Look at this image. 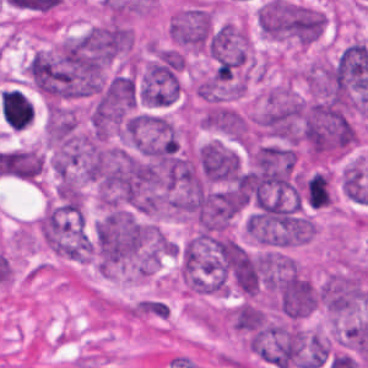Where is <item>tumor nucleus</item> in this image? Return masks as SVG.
I'll return each mask as SVG.
<instances>
[{"label": "tumor nucleus", "instance_id": "1", "mask_svg": "<svg viewBox=\"0 0 368 368\" xmlns=\"http://www.w3.org/2000/svg\"><path fill=\"white\" fill-rule=\"evenodd\" d=\"M292 117L300 148L311 160H327L348 152L357 141L350 107L315 94L300 96Z\"/></svg>", "mask_w": 368, "mask_h": 368}, {"label": "tumor nucleus", "instance_id": "2", "mask_svg": "<svg viewBox=\"0 0 368 368\" xmlns=\"http://www.w3.org/2000/svg\"><path fill=\"white\" fill-rule=\"evenodd\" d=\"M26 73L47 102L59 103L83 94L82 57L64 43L35 51L26 64Z\"/></svg>", "mask_w": 368, "mask_h": 368}, {"label": "tumor nucleus", "instance_id": "3", "mask_svg": "<svg viewBox=\"0 0 368 368\" xmlns=\"http://www.w3.org/2000/svg\"><path fill=\"white\" fill-rule=\"evenodd\" d=\"M185 56L175 48L151 46L136 77L135 98L145 106L171 107L182 92Z\"/></svg>", "mask_w": 368, "mask_h": 368}, {"label": "tumor nucleus", "instance_id": "4", "mask_svg": "<svg viewBox=\"0 0 368 368\" xmlns=\"http://www.w3.org/2000/svg\"><path fill=\"white\" fill-rule=\"evenodd\" d=\"M38 229L45 245L57 255L81 260L91 256V238L83 213L50 201Z\"/></svg>", "mask_w": 368, "mask_h": 368}, {"label": "tumor nucleus", "instance_id": "5", "mask_svg": "<svg viewBox=\"0 0 368 368\" xmlns=\"http://www.w3.org/2000/svg\"><path fill=\"white\" fill-rule=\"evenodd\" d=\"M300 95L284 85L268 86L256 111L258 133L296 146Z\"/></svg>", "mask_w": 368, "mask_h": 368}, {"label": "tumor nucleus", "instance_id": "6", "mask_svg": "<svg viewBox=\"0 0 368 368\" xmlns=\"http://www.w3.org/2000/svg\"><path fill=\"white\" fill-rule=\"evenodd\" d=\"M368 300V269L349 266L338 269L319 283L318 305L330 316L349 315Z\"/></svg>", "mask_w": 368, "mask_h": 368}, {"label": "tumor nucleus", "instance_id": "7", "mask_svg": "<svg viewBox=\"0 0 368 368\" xmlns=\"http://www.w3.org/2000/svg\"><path fill=\"white\" fill-rule=\"evenodd\" d=\"M324 13L291 0H271L270 35L274 39L307 46L319 38Z\"/></svg>", "mask_w": 368, "mask_h": 368}, {"label": "tumor nucleus", "instance_id": "8", "mask_svg": "<svg viewBox=\"0 0 368 368\" xmlns=\"http://www.w3.org/2000/svg\"><path fill=\"white\" fill-rule=\"evenodd\" d=\"M208 54L217 74L234 76L252 60V42L243 27L225 22L210 33Z\"/></svg>", "mask_w": 368, "mask_h": 368}, {"label": "tumor nucleus", "instance_id": "9", "mask_svg": "<svg viewBox=\"0 0 368 368\" xmlns=\"http://www.w3.org/2000/svg\"><path fill=\"white\" fill-rule=\"evenodd\" d=\"M213 26L212 4L192 2L172 14L168 37L174 46L205 52Z\"/></svg>", "mask_w": 368, "mask_h": 368}, {"label": "tumor nucleus", "instance_id": "10", "mask_svg": "<svg viewBox=\"0 0 368 368\" xmlns=\"http://www.w3.org/2000/svg\"><path fill=\"white\" fill-rule=\"evenodd\" d=\"M271 306L289 318L308 315L315 285L298 270L278 267L269 280Z\"/></svg>", "mask_w": 368, "mask_h": 368}, {"label": "tumor nucleus", "instance_id": "11", "mask_svg": "<svg viewBox=\"0 0 368 368\" xmlns=\"http://www.w3.org/2000/svg\"><path fill=\"white\" fill-rule=\"evenodd\" d=\"M197 164L200 176L210 184L230 182L237 178L242 167L239 153L217 140L201 145Z\"/></svg>", "mask_w": 368, "mask_h": 368}, {"label": "tumor nucleus", "instance_id": "12", "mask_svg": "<svg viewBox=\"0 0 368 368\" xmlns=\"http://www.w3.org/2000/svg\"><path fill=\"white\" fill-rule=\"evenodd\" d=\"M44 130L46 138L55 145L67 146L77 133L76 112L69 106L49 104Z\"/></svg>", "mask_w": 368, "mask_h": 368}, {"label": "tumor nucleus", "instance_id": "13", "mask_svg": "<svg viewBox=\"0 0 368 368\" xmlns=\"http://www.w3.org/2000/svg\"><path fill=\"white\" fill-rule=\"evenodd\" d=\"M55 198L66 211H83V190L78 177L71 172H59Z\"/></svg>", "mask_w": 368, "mask_h": 368}, {"label": "tumor nucleus", "instance_id": "14", "mask_svg": "<svg viewBox=\"0 0 368 368\" xmlns=\"http://www.w3.org/2000/svg\"><path fill=\"white\" fill-rule=\"evenodd\" d=\"M15 178L35 182L43 170V155L34 149L11 148Z\"/></svg>", "mask_w": 368, "mask_h": 368}]
</instances>
